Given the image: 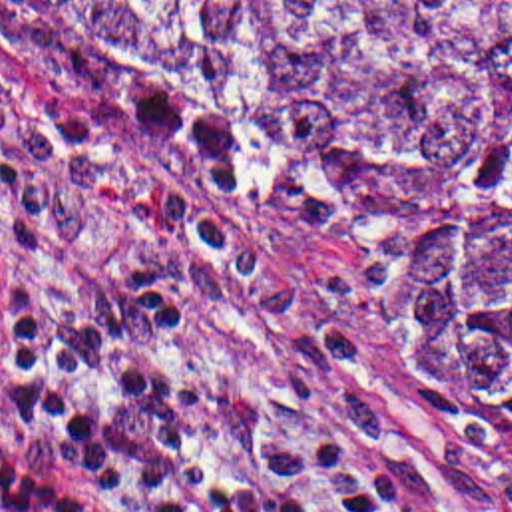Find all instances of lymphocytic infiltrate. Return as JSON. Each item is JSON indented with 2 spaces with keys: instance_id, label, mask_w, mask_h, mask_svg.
<instances>
[{
  "instance_id": "obj_1",
  "label": "lymphocytic infiltrate",
  "mask_w": 512,
  "mask_h": 512,
  "mask_svg": "<svg viewBox=\"0 0 512 512\" xmlns=\"http://www.w3.org/2000/svg\"><path fill=\"white\" fill-rule=\"evenodd\" d=\"M0 512H392V476L322 414L197 362L147 273L79 318L0 293Z\"/></svg>"
}]
</instances>
